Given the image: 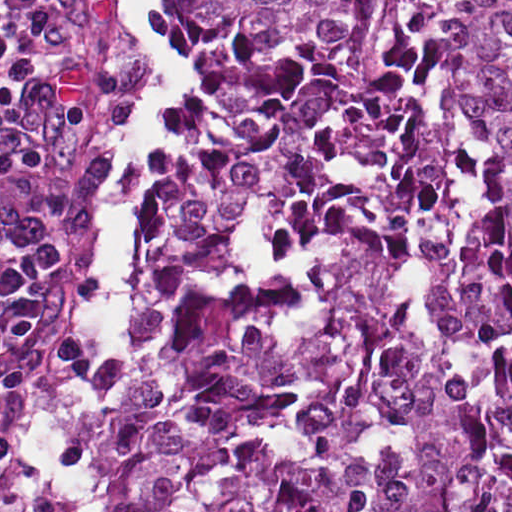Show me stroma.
<instances>
[{
  "label": "stroma",
  "instance_id": "obj_1",
  "mask_svg": "<svg viewBox=\"0 0 512 512\" xmlns=\"http://www.w3.org/2000/svg\"><path fill=\"white\" fill-rule=\"evenodd\" d=\"M172 0H149L146 15L165 35L183 77L177 99L158 101L152 112L169 119L149 137V178L143 217L135 225L133 267L122 290L125 344L99 358L73 334L93 294L100 265V204L119 168L128 127L142 97L148 65L139 49L136 0H28L21 24V79L49 116L65 160L77 229V261L56 296L53 327L64 362L91 372L97 418L90 440L87 512H110L107 477L112 464V398L131 361L128 289L139 263L157 193L197 140L204 99L195 76L170 41Z\"/></svg>",
  "mask_w": 512,
  "mask_h": 512
}]
</instances>
